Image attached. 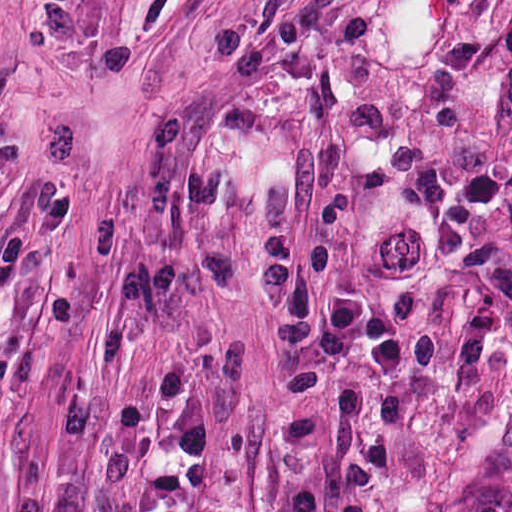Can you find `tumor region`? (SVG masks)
<instances>
[{
    "label": "tumor region",
    "instance_id": "obj_1",
    "mask_svg": "<svg viewBox=\"0 0 512 512\" xmlns=\"http://www.w3.org/2000/svg\"><path fill=\"white\" fill-rule=\"evenodd\" d=\"M422 512H512V498L443 490Z\"/></svg>",
    "mask_w": 512,
    "mask_h": 512
}]
</instances>
